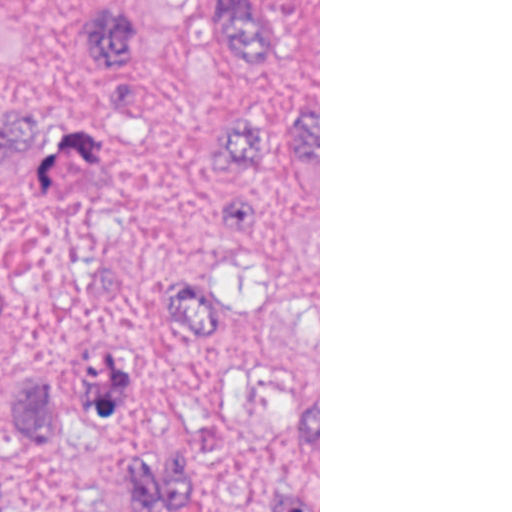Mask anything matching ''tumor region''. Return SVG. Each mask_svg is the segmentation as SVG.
I'll return each instance as SVG.
<instances>
[{
    "label": "tumor region",
    "mask_w": 512,
    "mask_h": 512,
    "mask_svg": "<svg viewBox=\"0 0 512 512\" xmlns=\"http://www.w3.org/2000/svg\"><path fill=\"white\" fill-rule=\"evenodd\" d=\"M226 54L271 58L281 0H213ZM136 136H215L254 176L221 211L236 278L186 283L172 322L232 366L234 419L212 449L176 441L157 404L122 376L83 393L29 386L38 457L0 476V512H318V87L277 114L224 100L208 111L56 128L25 174L53 195L101 148Z\"/></svg>",
    "instance_id": "e687c5a6"
}]
</instances>
